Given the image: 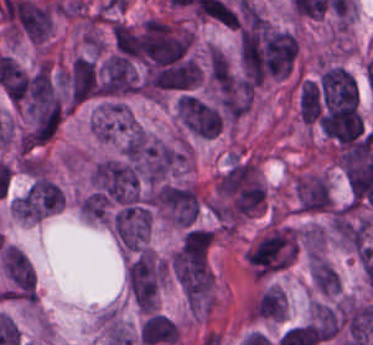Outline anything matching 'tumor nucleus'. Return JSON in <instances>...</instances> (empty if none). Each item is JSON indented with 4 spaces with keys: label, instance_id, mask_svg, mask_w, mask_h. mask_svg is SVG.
I'll return each instance as SVG.
<instances>
[{
    "label": "tumor nucleus",
    "instance_id": "2f306a5c",
    "mask_svg": "<svg viewBox=\"0 0 373 345\" xmlns=\"http://www.w3.org/2000/svg\"><path fill=\"white\" fill-rule=\"evenodd\" d=\"M159 206L174 224L191 227L199 212L196 191L188 186L164 184L159 193Z\"/></svg>",
    "mask_w": 373,
    "mask_h": 345
},
{
    "label": "tumor nucleus",
    "instance_id": "8643909e",
    "mask_svg": "<svg viewBox=\"0 0 373 345\" xmlns=\"http://www.w3.org/2000/svg\"><path fill=\"white\" fill-rule=\"evenodd\" d=\"M164 273L160 260L140 250L125 271V282L133 299L156 293Z\"/></svg>",
    "mask_w": 373,
    "mask_h": 345
},
{
    "label": "tumor nucleus",
    "instance_id": "5ab6c2c4",
    "mask_svg": "<svg viewBox=\"0 0 373 345\" xmlns=\"http://www.w3.org/2000/svg\"><path fill=\"white\" fill-rule=\"evenodd\" d=\"M177 112L182 123L200 137L211 138L220 129L222 117L217 108L199 98L184 93Z\"/></svg>",
    "mask_w": 373,
    "mask_h": 345
},
{
    "label": "tumor nucleus",
    "instance_id": "2cbd58db",
    "mask_svg": "<svg viewBox=\"0 0 373 345\" xmlns=\"http://www.w3.org/2000/svg\"><path fill=\"white\" fill-rule=\"evenodd\" d=\"M294 193L299 212L320 214L331 207L327 181L318 175H305L295 182Z\"/></svg>",
    "mask_w": 373,
    "mask_h": 345
},
{
    "label": "tumor nucleus",
    "instance_id": "3d1891a8",
    "mask_svg": "<svg viewBox=\"0 0 373 345\" xmlns=\"http://www.w3.org/2000/svg\"><path fill=\"white\" fill-rule=\"evenodd\" d=\"M309 275L317 291L324 294H336L338 276L325 261L312 257Z\"/></svg>",
    "mask_w": 373,
    "mask_h": 345
}]
</instances>
